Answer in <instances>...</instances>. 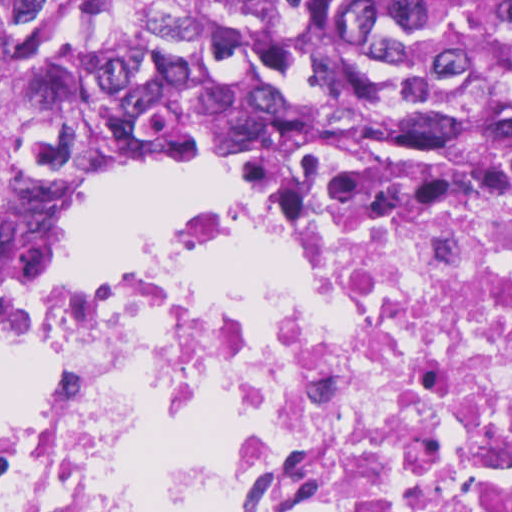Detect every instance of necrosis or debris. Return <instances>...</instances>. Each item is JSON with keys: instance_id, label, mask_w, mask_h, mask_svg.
<instances>
[{"instance_id": "1", "label": "necrosis or debris", "mask_w": 512, "mask_h": 512, "mask_svg": "<svg viewBox=\"0 0 512 512\" xmlns=\"http://www.w3.org/2000/svg\"><path fill=\"white\" fill-rule=\"evenodd\" d=\"M238 170L37 324L0 512H512V149Z\"/></svg>"}]
</instances>
